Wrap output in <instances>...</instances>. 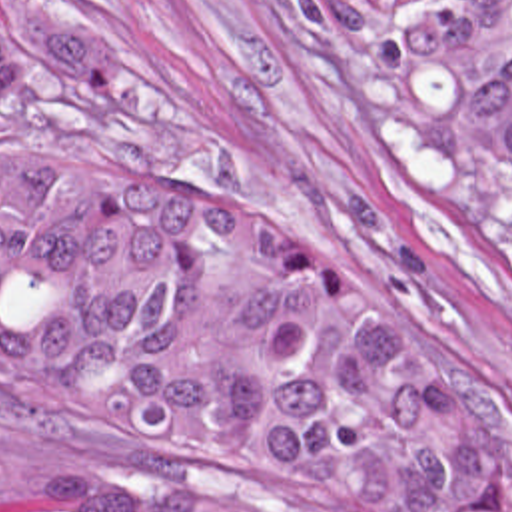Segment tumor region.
I'll use <instances>...</instances> for the list:
<instances>
[{
	"instance_id": "tumor-region-1",
	"label": "tumor region",
	"mask_w": 512,
	"mask_h": 512,
	"mask_svg": "<svg viewBox=\"0 0 512 512\" xmlns=\"http://www.w3.org/2000/svg\"><path fill=\"white\" fill-rule=\"evenodd\" d=\"M315 8L351 154L512 272V0ZM0 422L77 463L37 512H512L480 346L295 222L93 166L0 154Z\"/></svg>"
}]
</instances>
